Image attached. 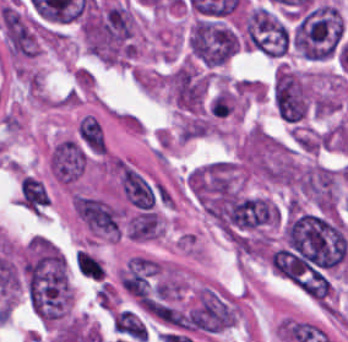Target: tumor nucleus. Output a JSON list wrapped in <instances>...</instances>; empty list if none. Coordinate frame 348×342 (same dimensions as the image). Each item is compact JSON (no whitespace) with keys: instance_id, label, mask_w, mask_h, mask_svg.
<instances>
[{"instance_id":"1","label":"tumor nucleus","mask_w":348,"mask_h":342,"mask_svg":"<svg viewBox=\"0 0 348 342\" xmlns=\"http://www.w3.org/2000/svg\"><path fill=\"white\" fill-rule=\"evenodd\" d=\"M344 38L341 12L335 4L318 1L299 13L290 25L295 52L312 61L335 58Z\"/></svg>"},{"instance_id":"2","label":"tumor nucleus","mask_w":348,"mask_h":342,"mask_svg":"<svg viewBox=\"0 0 348 342\" xmlns=\"http://www.w3.org/2000/svg\"><path fill=\"white\" fill-rule=\"evenodd\" d=\"M191 52L205 65H220L235 52L236 36L220 24L198 20L188 40Z\"/></svg>"},{"instance_id":"3","label":"tumor nucleus","mask_w":348,"mask_h":342,"mask_svg":"<svg viewBox=\"0 0 348 342\" xmlns=\"http://www.w3.org/2000/svg\"><path fill=\"white\" fill-rule=\"evenodd\" d=\"M245 32L248 46L268 54L288 51V31L267 9L255 8L246 17Z\"/></svg>"},{"instance_id":"4","label":"tumor nucleus","mask_w":348,"mask_h":342,"mask_svg":"<svg viewBox=\"0 0 348 342\" xmlns=\"http://www.w3.org/2000/svg\"><path fill=\"white\" fill-rule=\"evenodd\" d=\"M273 101L278 115L289 121H297L308 109L306 92L300 78L280 66L274 77Z\"/></svg>"}]
</instances>
